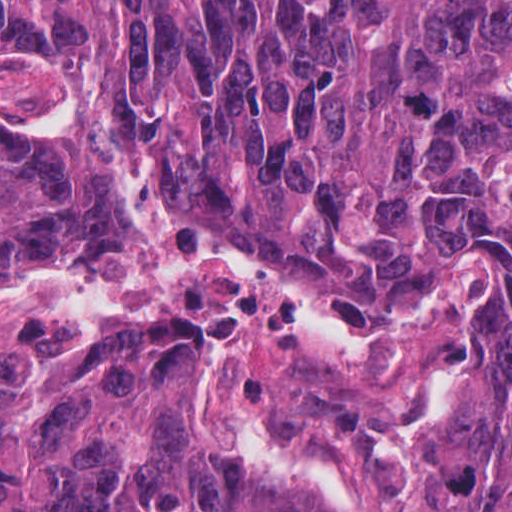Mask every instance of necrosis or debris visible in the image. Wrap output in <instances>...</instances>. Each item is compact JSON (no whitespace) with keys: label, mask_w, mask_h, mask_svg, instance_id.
<instances>
[{"label":"necrosis or debris","mask_w":512,"mask_h":512,"mask_svg":"<svg viewBox=\"0 0 512 512\" xmlns=\"http://www.w3.org/2000/svg\"><path fill=\"white\" fill-rule=\"evenodd\" d=\"M0 129L82 163L119 216L107 260L0 283V373L69 359L111 321L186 322L209 337L191 397L208 431L277 455L348 512H429L415 441L447 410L491 260L453 258L388 330L351 333L294 283L190 235L45 69L0 63Z\"/></svg>","instance_id":"obj_1"}]
</instances>
